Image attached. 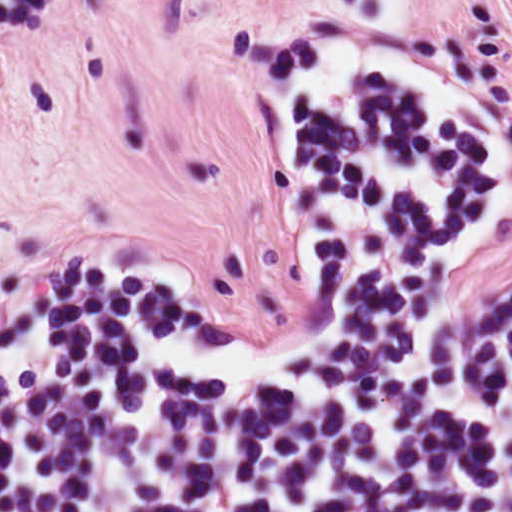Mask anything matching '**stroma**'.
<instances>
[{
  "mask_svg": "<svg viewBox=\"0 0 512 512\" xmlns=\"http://www.w3.org/2000/svg\"><path fill=\"white\" fill-rule=\"evenodd\" d=\"M387 57L512 116V0ZM297 97L0 228V336L32 275L88 253L150 261L179 301L243 332L292 328L303 309L287 208ZM511 293L512 227L466 276L462 304Z\"/></svg>",
  "mask_w": 512,
  "mask_h": 512,
  "instance_id": "35a3bbf8",
  "label": "stroma"
}]
</instances>
